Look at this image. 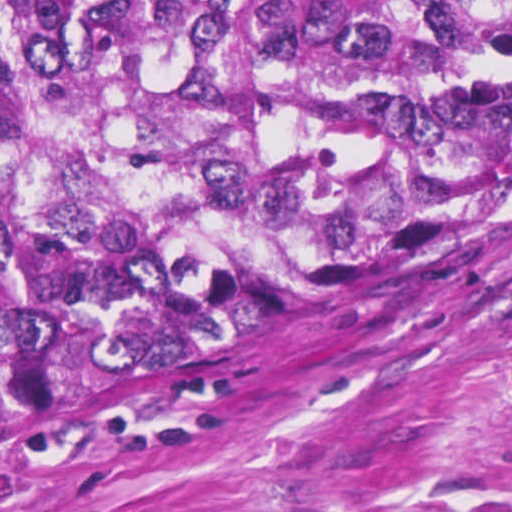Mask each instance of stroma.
<instances>
[{
	"label": "stroma",
	"instance_id": "35a3bbf8",
	"mask_svg": "<svg viewBox=\"0 0 512 512\" xmlns=\"http://www.w3.org/2000/svg\"><path fill=\"white\" fill-rule=\"evenodd\" d=\"M406 275L287 305L0 449V512H512V196Z\"/></svg>",
	"mask_w": 512,
	"mask_h": 512
}]
</instances>
